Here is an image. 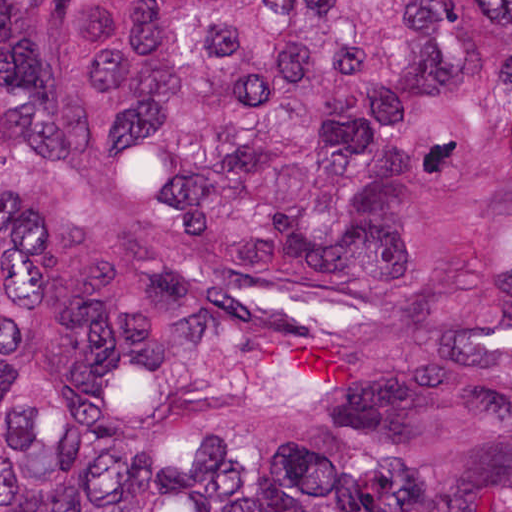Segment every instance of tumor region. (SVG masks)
<instances>
[{
    "label": "tumor region",
    "mask_w": 512,
    "mask_h": 512,
    "mask_svg": "<svg viewBox=\"0 0 512 512\" xmlns=\"http://www.w3.org/2000/svg\"><path fill=\"white\" fill-rule=\"evenodd\" d=\"M0 512H512V0H0Z\"/></svg>",
    "instance_id": "1"
}]
</instances>
